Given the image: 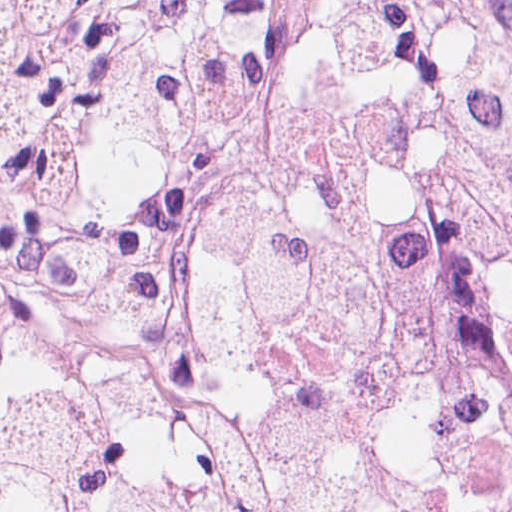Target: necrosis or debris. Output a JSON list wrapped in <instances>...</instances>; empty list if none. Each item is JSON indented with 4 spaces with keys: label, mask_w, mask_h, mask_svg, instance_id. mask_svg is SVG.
Listing matches in <instances>:
<instances>
[{
    "label": "necrosis or debris",
    "mask_w": 512,
    "mask_h": 512,
    "mask_svg": "<svg viewBox=\"0 0 512 512\" xmlns=\"http://www.w3.org/2000/svg\"><path fill=\"white\" fill-rule=\"evenodd\" d=\"M0 512H512V0H0Z\"/></svg>",
    "instance_id": "1"
}]
</instances>
